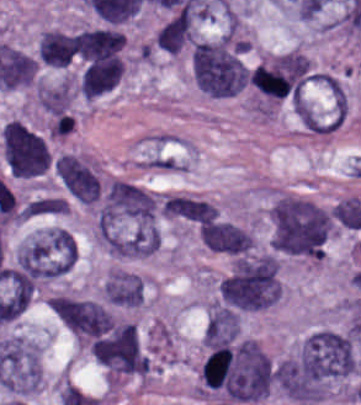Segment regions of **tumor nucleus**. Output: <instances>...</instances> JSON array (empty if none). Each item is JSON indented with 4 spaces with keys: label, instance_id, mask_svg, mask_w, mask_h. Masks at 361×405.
<instances>
[{
    "label": "tumor nucleus",
    "instance_id": "2f306a5c",
    "mask_svg": "<svg viewBox=\"0 0 361 405\" xmlns=\"http://www.w3.org/2000/svg\"><path fill=\"white\" fill-rule=\"evenodd\" d=\"M354 372L349 333L319 329L300 342L277 365V386L290 399L321 401L348 382Z\"/></svg>",
    "mask_w": 361,
    "mask_h": 405
},
{
    "label": "tumor nucleus",
    "instance_id": "8643909e",
    "mask_svg": "<svg viewBox=\"0 0 361 405\" xmlns=\"http://www.w3.org/2000/svg\"><path fill=\"white\" fill-rule=\"evenodd\" d=\"M330 225L329 213L315 203L279 196L271 209L272 247L321 260Z\"/></svg>",
    "mask_w": 361,
    "mask_h": 405
},
{
    "label": "tumor nucleus",
    "instance_id": "5ab6c2c4",
    "mask_svg": "<svg viewBox=\"0 0 361 405\" xmlns=\"http://www.w3.org/2000/svg\"><path fill=\"white\" fill-rule=\"evenodd\" d=\"M247 44L227 35L195 42L193 76L198 90L212 96H231L246 82Z\"/></svg>",
    "mask_w": 361,
    "mask_h": 405
},
{
    "label": "tumor nucleus",
    "instance_id": "2cbd58db",
    "mask_svg": "<svg viewBox=\"0 0 361 405\" xmlns=\"http://www.w3.org/2000/svg\"><path fill=\"white\" fill-rule=\"evenodd\" d=\"M220 285L236 307L253 311L275 304L282 296L278 259L272 253L235 259Z\"/></svg>",
    "mask_w": 361,
    "mask_h": 405
},
{
    "label": "tumor nucleus",
    "instance_id": "3d1891a8",
    "mask_svg": "<svg viewBox=\"0 0 361 405\" xmlns=\"http://www.w3.org/2000/svg\"><path fill=\"white\" fill-rule=\"evenodd\" d=\"M75 253L66 229L47 227L22 240L14 253V268L34 282H50L68 274Z\"/></svg>",
    "mask_w": 361,
    "mask_h": 405
},
{
    "label": "tumor nucleus",
    "instance_id": "2083b535",
    "mask_svg": "<svg viewBox=\"0 0 361 405\" xmlns=\"http://www.w3.org/2000/svg\"><path fill=\"white\" fill-rule=\"evenodd\" d=\"M92 353L113 382L147 376V356L136 324L103 338Z\"/></svg>",
    "mask_w": 361,
    "mask_h": 405
},
{
    "label": "tumor nucleus",
    "instance_id": "8087334f",
    "mask_svg": "<svg viewBox=\"0 0 361 405\" xmlns=\"http://www.w3.org/2000/svg\"><path fill=\"white\" fill-rule=\"evenodd\" d=\"M1 150L3 162L13 176L30 179L48 170L51 149L29 126L1 133Z\"/></svg>",
    "mask_w": 361,
    "mask_h": 405
},
{
    "label": "tumor nucleus",
    "instance_id": "c2bd9aea",
    "mask_svg": "<svg viewBox=\"0 0 361 405\" xmlns=\"http://www.w3.org/2000/svg\"><path fill=\"white\" fill-rule=\"evenodd\" d=\"M55 172L65 189L82 202H95L100 179L84 157L72 152L60 154Z\"/></svg>",
    "mask_w": 361,
    "mask_h": 405
},
{
    "label": "tumor nucleus",
    "instance_id": "feef74b5",
    "mask_svg": "<svg viewBox=\"0 0 361 405\" xmlns=\"http://www.w3.org/2000/svg\"><path fill=\"white\" fill-rule=\"evenodd\" d=\"M204 244L212 250L240 254L253 245V236L242 227L230 221L209 223L202 231Z\"/></svg>",
    "mask_w": 361,
    "mask_h": 405
},
{
    "label": "tumor nucleus",
    "instance_id": "3e47fb67",
    "mask_svg": "<svg viewBox=\"0 0 361 405\" xmlns=\"http://www.w3.org/2000/svg\"><path fill=\"white\" fill-rule=\"evenodd\" d=\"M240 324V312L217 302H210L204 324V344L232 342L240 333Z\"/></svg>",
    "mask_w": 361,
    "mask_h": 405
},
{
    "label": "tumor nucleus",
    "instance_id": "f7901128",
    "mask_svg": "<svg viewBox=\"0 0 361 405\" xmlns=\"http://www.w3.org/2000/svg\"><path fill=\"white\" fill-rule=\"evenodd\" d=\"M193 203L194 196L184 192H171L161 199L160 213L192 222Z\"/></svg>",
    "mask_w": 361,
    "mask_h": 405
},
{
    "label": "tumor nucleus",
    "instance_id": "268c6acd",
    "mask_svg": "<svg viewBox=\"0 0 361 405\" xmlns=\"http://www.w3.org/2000/svg\"><path fill=\"white\" fill-rule=\"evenodd\" d=\"M33 216L63 214L56 195H42L30 199L26 204Z\"/></svg>",
    "mask_w": 361,
    "mask_h": 405
}]
</instances>
